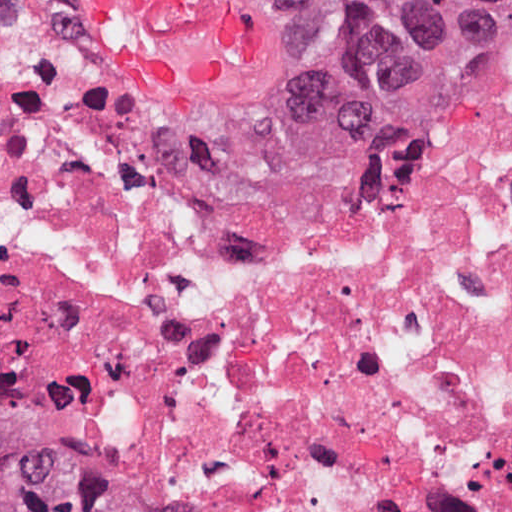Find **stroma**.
<instances>
[{
	"mask_svg": "<svg viewBox=\"0 0 512 512\" xmlns=\"http://www.w3.org/2000/svg\"><path fill=\"white\" fill-rule=\"evenodd\" d=\"M265 16V51L239 78L190 97H161L110 61L84 27L103 70L136 109L168 131H248L262 124L291 128L362 165H410L445 151L484 111L512 96V58L498 67L483 99L457 125L412 146L367 155L341 134L330 80V48L311 0H236ZM85 384V383H84ZM90 396L202 512H219L187 487L153 448L85 384Z\"/></svg>",
	"mask_w": 512,
	"mask_h": 512,
	"instance_id": "1",
	"label": "stroma"
}]
</instances>
